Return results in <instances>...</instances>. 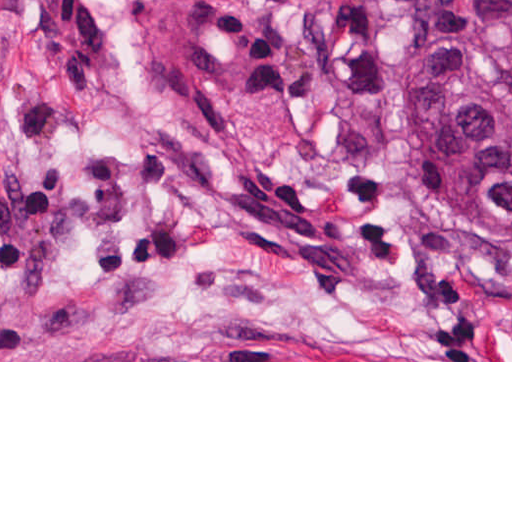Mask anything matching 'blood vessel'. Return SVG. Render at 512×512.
Here are the masks:
<instances>
[{
	"label": "blood vessel",
	"mask_w": 512,
	"mask_h": 512,
	"mask_svg": "<svg viewBox=\"0 0 512 512\" xmlns=\"http://www.w3.org/2000/svg\"><path fill=\"white\" fill-rule=\"evenodd\" d=\"M199 0H46L52 52L115 59L172 27Z\"/></svg>",
	"instance_id": "8fb6f2fc"
}]
</instances>
